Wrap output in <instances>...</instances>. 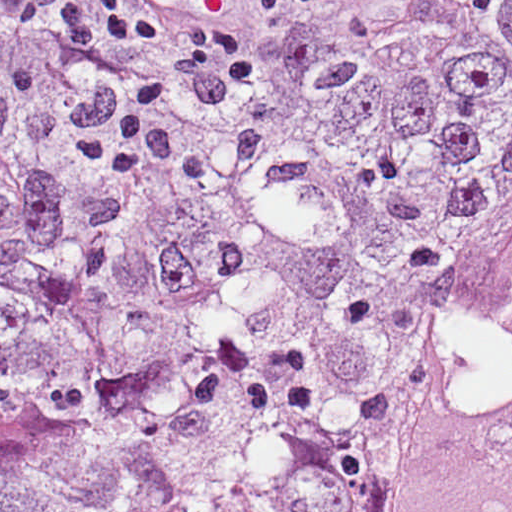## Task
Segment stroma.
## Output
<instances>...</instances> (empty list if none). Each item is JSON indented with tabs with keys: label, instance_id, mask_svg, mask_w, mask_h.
Returning <instances> with one entry per match:
<instances>
[{
	"label": "stroma",
	"instance_id": "stroma-1",
	"mask_svg": "<svg viewBox=\"0 0 512 512\" xmlns=\"http://www.w3.org/2000/svg\"><path fill=\"white\" fill-rule=\"evenodd\" d=\"M137 97L76 47L65 11L18 22L13 0H0V101L10 106L35 176H59L97 154ZM17 197L0 185V213Z\"/></svg>",
	"mask_w": 512,
	"mask_h": 512
}]
</instances>
